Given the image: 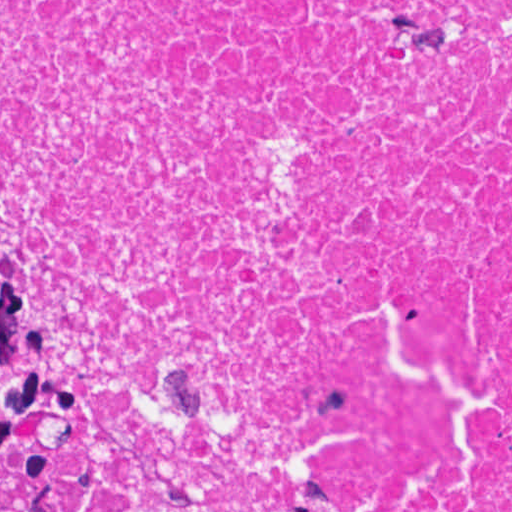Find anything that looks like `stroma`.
Returning <instances> with one entry per match:
<instances>
[{"mask_svg": "<svg viewBox=\"0 0 512 512\" xmlns=\"http://www.w3.org/2000/svg\"><path fill=\"white\" fill-rule=\"evenodd\" d=\"M0 321L30 401L56 439L60 460L72 479L77 512V454L69 410L22 328L1 273Z\"/></svg>", "mask_w": 512, "mask_h": 512, "instance_id": "stroma-1", "label": "stroma"}]
</instances>
